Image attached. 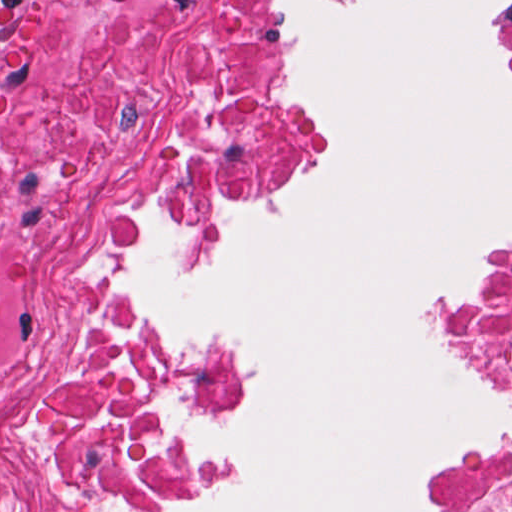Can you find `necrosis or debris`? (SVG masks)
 Segmentation results:
<instances>
[{
    "instance_id": "4bbe7bcc",
    "label": "necrosis or debris",
    "mask_w": 512,
    "mask_h": 512,
    "mask_svg": "<svg viewBox=\"0 0 512 512\" xmlns=\"http://www.w3.org/2000/svg\"><path fill=\"white\" fill-rule=\"evenodd\" d=\"M64 9L49 102L0 122V512H205L181 435L226 377L142 286L147 217L259 188L304 106L264 0ZM477 329L512 375V246Z\"/></svg>"
}]
</instances>
